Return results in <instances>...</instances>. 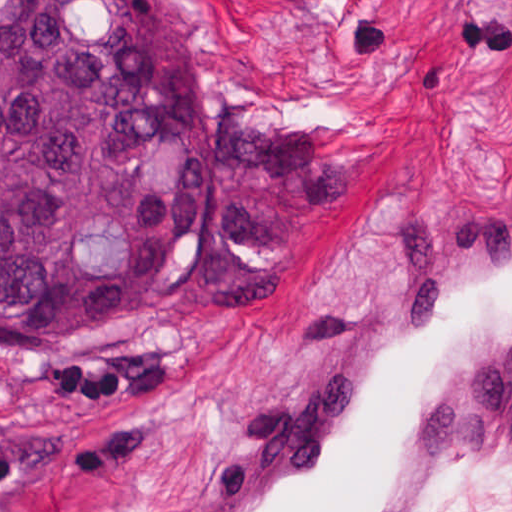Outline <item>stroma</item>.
<instances>
[{"label":"stroma","mask_w":512,"mask_h":512,"mask_svg":"<svg viewBox=\"0 0 512 512\" xmlns=\"http://www.w3.org/2000/svg\"><path fill=\"white\" fill-rule=\"evenodd\" d=\"M179 4L206 99L322 127L343 194L283 242L270 304L0 346V512H174L340 339L421 217L512 185V0ZM428 512H512V430L472 442Z\"/></svg>","instance_id":"stroma-1"}]
</instances>
